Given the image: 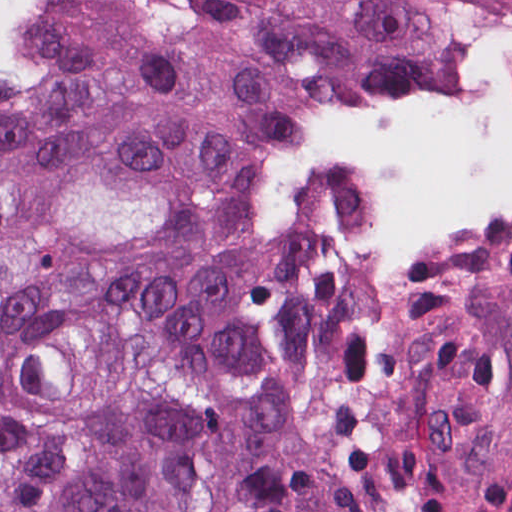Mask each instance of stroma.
Here are the masks:
<instances>
[{
    "label": "stroma",
    "mask_w": 512,
    "mask_h": 512,
    "mask_svg": "<svg viewBox=\"0 0 512 512\" xmlns=\"http://www.w3.org/2000/svg\"><path fill=\"white\" fill-rule=\"evenodd\" d=\"M59 1H102L162 13L195 28L223 52L257 57L222 19L185 4L184 0H29L26 7ZM98 33L88 27H59ZM122 41L234 93L263 175L288 251L317 259H382L358 248L309 212L290 183L278 152L259 122L221 52L136 41ZM441 86L489 91L512 89V74L486 68L459 70ZM404 259H512V249L488 253H407Z\"/></svg>",
    "instance_id": "stroma-1"
}]
</instances>
